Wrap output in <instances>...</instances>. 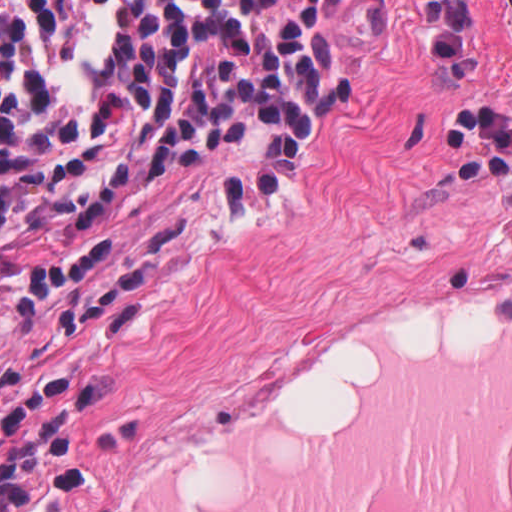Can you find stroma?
I'll return each instance as SVG.
<instances>
[{
	"mask_svg": "<svg viewBox=\"0 0 512 512\" xmlns=\"http://www.w3.org/2000/svg\"><path fill=\"white\" fill-rule=\"evenodd\" d=\"M347 99L249 205L268 121L0 262V452L512 156V0H339Z\"/></svg>",
	"mask_w": 512,
	"mask_h": 512,
	"instance_id": "35a3bbf8",
	"label": "stroma"
}]
</instances>
